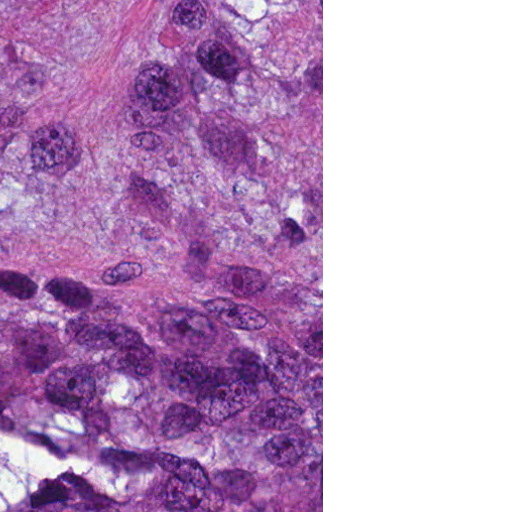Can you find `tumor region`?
<instances>
[{
  "mask_svg": "<svg viewBox=\"0 0 512 512\" xmlns=\"http://www.w3.org/2000/svg\"><path fill=\"white\" fill-rule=\"evenodd\" d=\"M0 512H161V0H0Z\"/></svg>",
  "mask_w": 512,
  "mask_h": 512,
  "instance_id": "tumor-region-1",
  "label": "tumor region"
}]
</instances>
